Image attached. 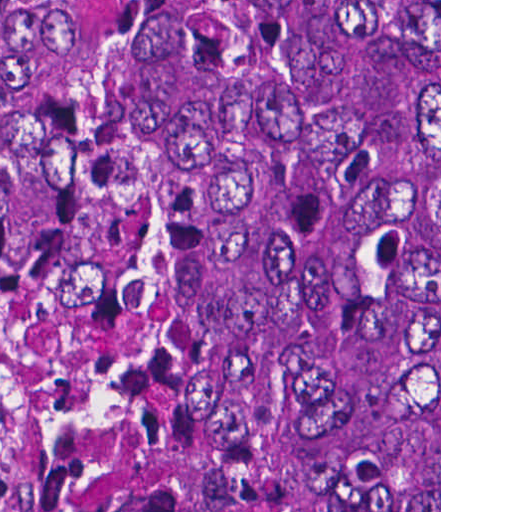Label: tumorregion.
Instances as JSON below:
<instances>
[{
	"label": "tumor region",
	"mask_w": 512,
	"mask_h": 512,
	"mask_svg": "<svg viewBox=\"0 0 512 512\" xmlns=\"http://www.w3.org/2000/svg\"><path fill=\"white\" fill-rule=\"evenodd\" d=\"M0 512H439V0H49Z\"/></svg>",
	"instance_id": "1"
}]
</instances>
